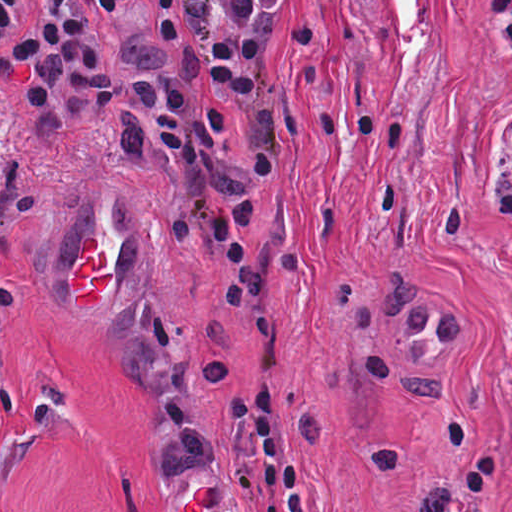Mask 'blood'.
Returning a JSON list of instances; mask_svg holds the SVG:
<instances>
[{"mask_svg": "<svg viewBox=\"0 0 512 512\" xmlns=\"http://www.w3.org/2000/svg\"><path fill=\"white\" fill-rule=\"evenodd\" d=\"M104 260L96 239L87 237L81 263L69 277L76 305H96L101 300V288L108 283Z\"/></svg>", "mask_w": 512, "mask_h": 512, "instance_id": "1", "label": "blood"}]
</instances>
